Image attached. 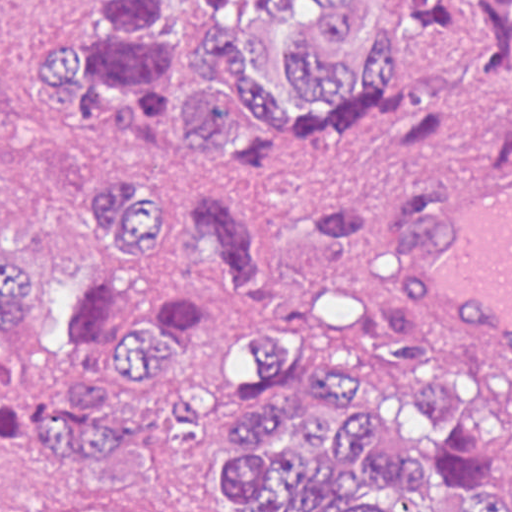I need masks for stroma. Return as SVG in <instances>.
<instances>
[{
	"mask_svg": "<svg viewBox=\"0 0 512 512\" xmlns=\"http://www.w3.org/2000/svg\"><path fill=\"white\" fill-rule=\"evenodd\" d=\"M76 1L0 0V512H144L136 493L40 469L7 442L17 415L64 383L53 325L59 301L85 281L80 223L97 183L100 140L75 127L46 89L32 87L26 68L32 48L50 44ZM510 115L512 89L499 86L474 100L465 131L452 129L410 152H392L397 123L337 136H246L236 148L217 150L210 166L262 192L273 231L303 206L325 202H348L382 227L388 194L406 170H426L445 183L512 177V169H487L490 140ZM304 274L301 246L288 245L273 260L270 304L238 303L224 336L183 385L207 394L211 411L187 455L205 512H232L214 498L211 479L226 456L230 411L249 397L245 325L280 319L317 358L338 355L309 341L296 321L292 294ZM425 335L451 378L497 376ZM354 387L367 407L356 379ZM378 434L385 448H402ZM496 488L512 493V461ZM466 499L438 492L426 512H455Z\"/></svg>",
	"mask_w": 512,
	"mask_h": 512,
	"instance_id": "stroma-1",
	"label": "stroma"
}]
</instances>
